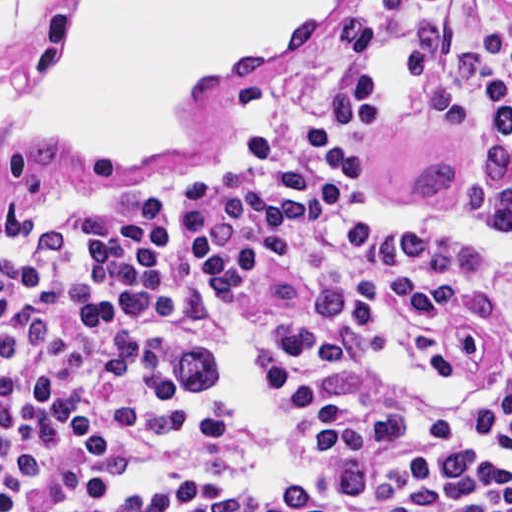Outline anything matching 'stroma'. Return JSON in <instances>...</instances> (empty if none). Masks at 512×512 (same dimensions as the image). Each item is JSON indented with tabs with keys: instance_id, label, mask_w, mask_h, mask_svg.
Wrapping results in <instances>:
<instances>
[{
	"instance_id": "1",
	"label": "stroma",
	"mask_w": 512,
	"mask_h": 512,
	"mask_svg": "<svg viewBox=\"0 0 512 512\" xmlns=\"http://www.w3.org/2000/svg\"><path fill=\"white\" fill-rule=\"evenodd\" d=\"M70 0L35 7L0 42L21 64L30 103L52 85V51ZM357 16L380 28V47L359 53L327 30ZM445 18L483 41L512 30V0H336L323 16L212 73L181 99V149L138 169L90 161L56 146H0V249L41 219L70 207L116 203L142 191L180 186L219 162L227 147L293 112L329 83L418 44L420 28Z\"/></svg>"
}]
</instances>
